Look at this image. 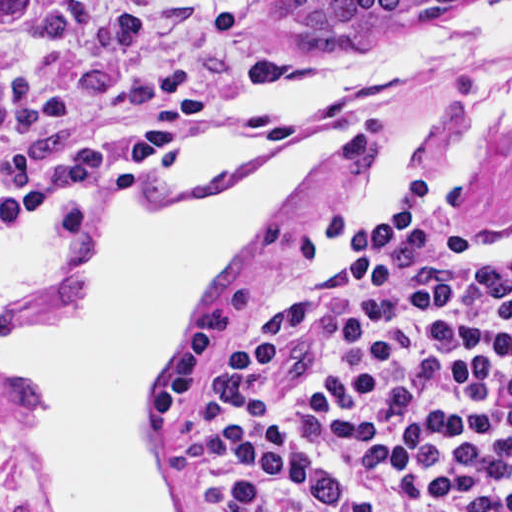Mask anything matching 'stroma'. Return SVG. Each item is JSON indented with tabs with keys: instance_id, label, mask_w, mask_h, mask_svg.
I'll list each match as a JSON object with an SVG mask.
<instances>
[{
	"instance_id": "obj_1",
	"label": "stroma",
	"mask_w": 512,
	"mask_h": 512,
	"mask_svg": "<svg viewBox=\"0 0 512 512\" xmlns=\"http://www.w3.org/2000/svg\"><path fill=\"white\" fill-rule=\"evenodd\" d=\"M310 1H408L339 28H309ZM482 0H0V336L77 312L94 286L96 214L130 186L139 143L212 134L250 74L388 49ZM512 42L482 66L428 83L374 85L312 113L349 123L283 194L218 295L186 332L158 402L172 512H200L201 376L214 340L291 308L277 287L305 221L333 180L417 112L504 79ZM421 185L408 187L375 223ZM429 230L480 252L512 249V147L450 193L432 190ZM0 512H57L28 447L16 396L0 385Z\"/></svg>"
}]
</instances>
